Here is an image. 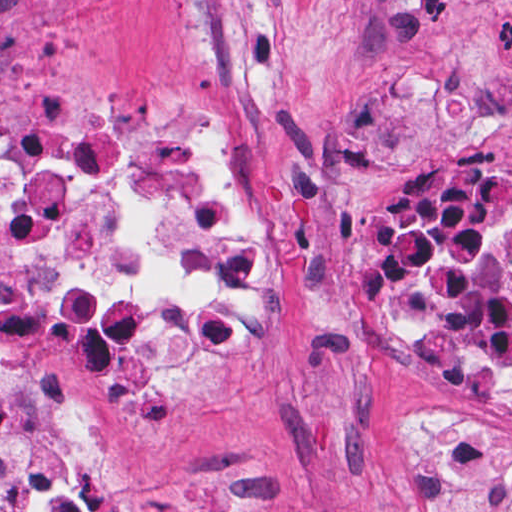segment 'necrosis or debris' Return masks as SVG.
I'll list each match as a JSON object with an SVG mask.
<instances>
[{"mask_svg":"<svg viewBox=\"0 0 512 512\" xmlns=\"http://www.w3.org/2000/svg\"><path fill=\"white\" fill-rule=\"evenodd\" d=\"M270 257L264 195L190 103L110 129L0 111V321L32 323L87 384L178 396L257 320ZM362 335L512 401V167L436 164L382 199ZM105 442L0 362V488L22 512H118Z\"/></svg>","mask_w":512,"mask_h":512,"instance_id":"necrosis-or-debris-1","label":"necrosis or debris"}]
</instances>
